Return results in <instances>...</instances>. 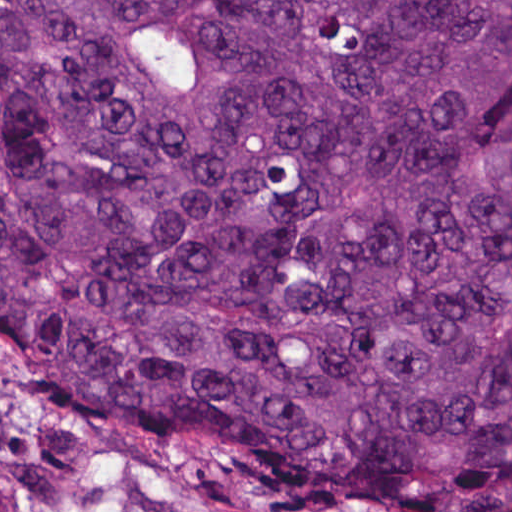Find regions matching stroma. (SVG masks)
Instances as JSON below:
<instances>
[{
  "label": "stroma",
  "mask_w": 512,
  "mask_h": 512,
  "mask_svg": "<svg viewBox=\"0 0 512 512\" xmlns=\"http://www.w3.org/2000/svg\"><path fill=\"white\" fill-rule=\"evenodd\" d=\"M0 512H334L154 417H39L0 355Z\"/></svg>",
  "instance_id": "stroma-1"
}]
</instances>
